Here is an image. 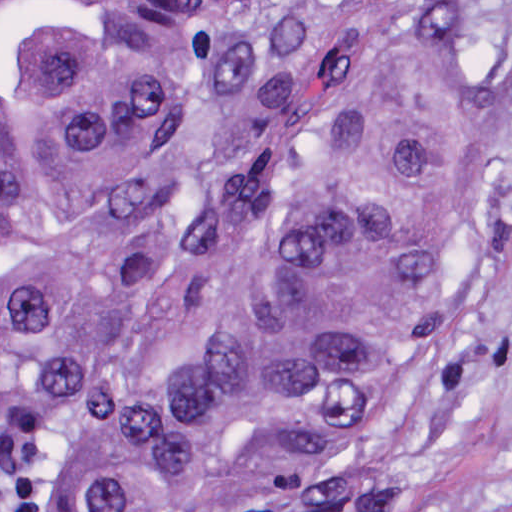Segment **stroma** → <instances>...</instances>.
I'll list each match as a JSON object with an SVG mask.
<instances>
[{
	"label": "stroma",
	"mask_w": 512,
	"mask_h": 512,
	"mask_svg": "<svg viewBox=\"0 0 512 512\" xmlns=\"http://www.w3.org/2000/svg\"><path fill=\"white\" fill-rule=\"evenodd\" d=\"M479 1L455 57L512 60V0ZM155 512H512V161L461 253L405 308V401L384 431L193 511L60 468Z\"/></svg>",
	"instance_id": "obj_1"
}]
</instances>
